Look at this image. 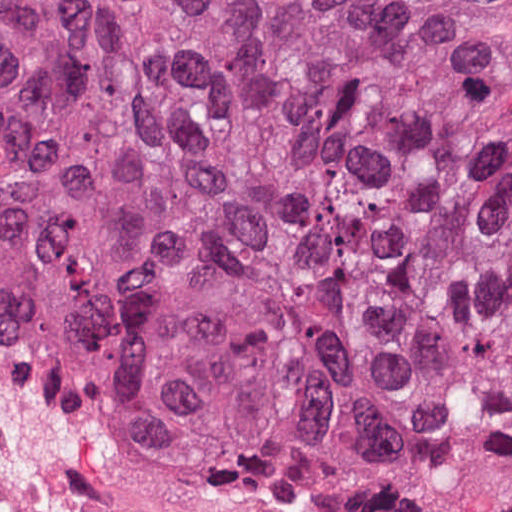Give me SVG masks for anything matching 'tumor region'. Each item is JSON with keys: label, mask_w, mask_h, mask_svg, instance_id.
Listing matches in <instances>:
<instances>
[{"label": "tumor region", "mask_w": 512, "mask_h": 512, "mask_svg": "<svg viewBox=\"0 0 512 512\" xmlns=\"http://www.w3.org/2000/svg\"><path fill=\"white\" fill-rule=\"evenodd\" d=\"M511 74L505 0H0V338L229 502L512 425Z\"/></svg>", "instance_id": "e687c5a6"}]
</instances>
